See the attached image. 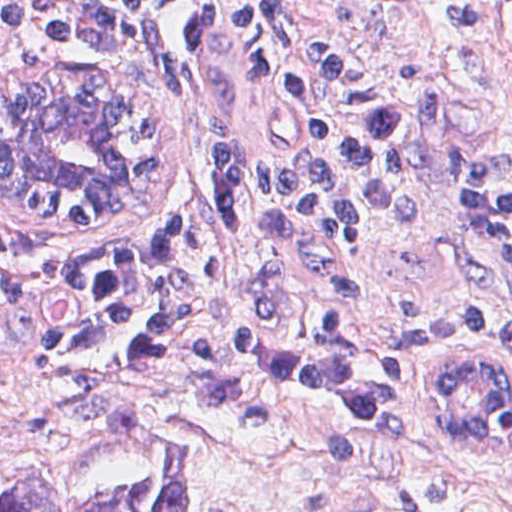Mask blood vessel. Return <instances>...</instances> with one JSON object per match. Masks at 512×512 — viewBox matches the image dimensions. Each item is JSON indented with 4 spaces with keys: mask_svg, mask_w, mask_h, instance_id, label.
<instances>
[{
    "mask_svg": "<svg viewBox=\"0 0 512 512\" xmlns=\"http://www.w3.org/2000/svg\"><path fill=\"white\" fill-rule=\"evenodd\" d=\"M339 21L367 36H385L402 19L405 0H316Z\"/></svg>",
    "mask_w": 512,
    "mask_h": 512,
    "instance_id": "1",
    "label": "blood vessel"
}]
</instances>
